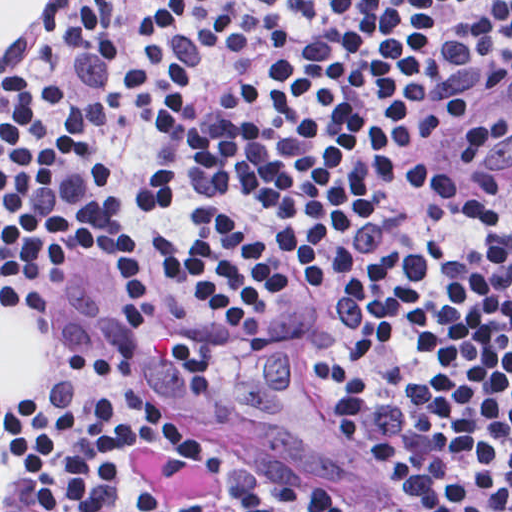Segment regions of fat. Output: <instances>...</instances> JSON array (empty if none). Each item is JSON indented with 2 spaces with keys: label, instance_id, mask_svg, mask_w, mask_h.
<instances>
[{
  "label": "fat",
  "instance_id": "1",
  "mask_svg": "<svg viewBox=\"0 0 512 512\" xmlns=\"http://www.w3.org/2000/svg\"><path fill=\"white\" fill-rule=\"evenodd\" d=\"M49 1H0V46H13L38 23ZM47 377V329L23 306L0 303V401L19 403Z\"/></svg>",
  "mask_w": 512,
  "mask_h": 512
}]
</instances>
